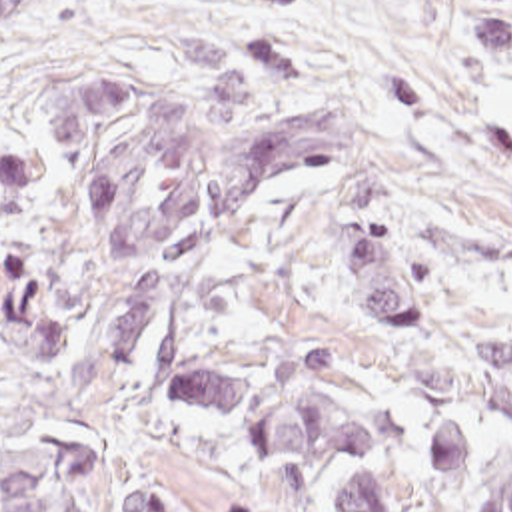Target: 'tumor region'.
<instances>
[{"label":"tumor region","mask_w":512,"mask_h":512,"mask_svg":"<svg viewBox=\"0 0 512 512\" xmlns=\"http://www.w3.org/2000/svg\"><path fill=\"white\" fill-rule=\"evenodd\" d=\"M242 18H286L306 0H234ZM20 0H0V24ZM252 76L214 84V128L124 76L82 78L44 108L62 194L118 292L104 366L154 380L158 404L232 427L246 455L304 471L332 512H401L388 459L401 406L360 354L274 332L220 330L222 274L250 214L304 172L326 196L332 284L376 334L417 332L451 272L512 268V230L451 216L415 222L392 166L356 112L288 110L250 126ZM473 370L512 376V340L473 342ZM435 512H512V439L491 415L447 406L427 419ZM166 469V467H164ZM168 473V469H166ZM142 459L92 437L0 447V512H182Z\"/></svg>","instance_id":"obj_1"}]
</instances>
